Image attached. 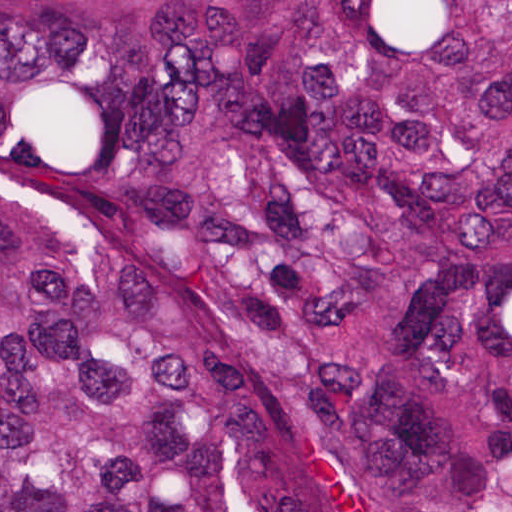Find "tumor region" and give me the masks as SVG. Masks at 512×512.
<instances>
[{
	"label": "tumor region",
	"instance_id": "1",
	"mask_svg": "<svg viewBox=\"0 0 512 512\" xmlns=\"http://www.w3.org/2000/svg\"><path fill=\"white\" fill-rule=\"evenodd\" d=\"M0 512H512V0H0Z\"/></svg>",
	"mask_w": 512,
	"mask_h": 512
}]
</instances>
